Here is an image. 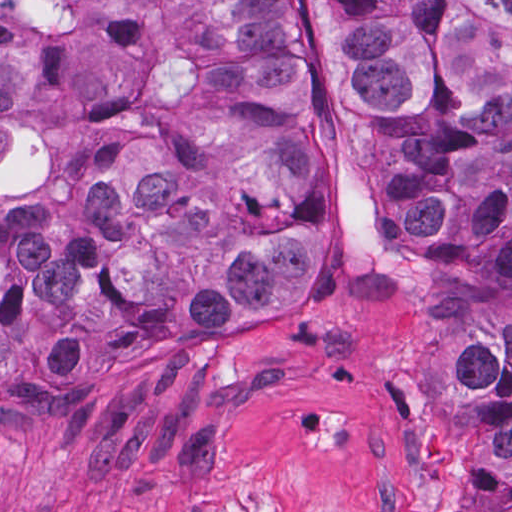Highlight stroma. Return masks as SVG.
Returning a JSON list of instances; mask_svg holds the SVG:
<instances>
[{
  "label": "stroma",
  "instance_id": "obj_1",
  "mask_svg": "<svg viewBox=\"0 0 512 512\" xmlns=\"http://www.w3.org/2000/svg\"><path fill=\"white\" fill-rule=\"evenodd\" d=\"M280 2L320 133L316 306L0 405V512H455L321 0Z\"/></svg>",
  "mask_w": 512,
  "mask_h": 512
}]
</instances>
